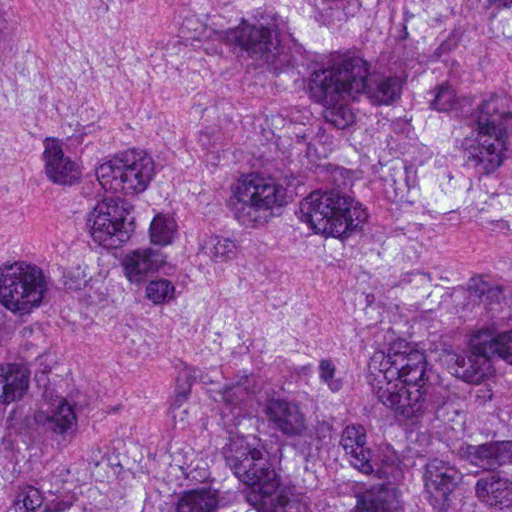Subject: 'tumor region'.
<instances>
[{"mask_svg": "<svg viewBox=\"0 0 512 512\" xmlns=\"http://www.w3.org/2000/svg\"><path fill=\"white\" fill-rule=\"evenodd\" d=\"M0 512H512V0H0Z\"/></svg>", "mask_w": 512, "mask_h": 512, "instance_id": "1", "label": "tumor region"}]
</instances>
